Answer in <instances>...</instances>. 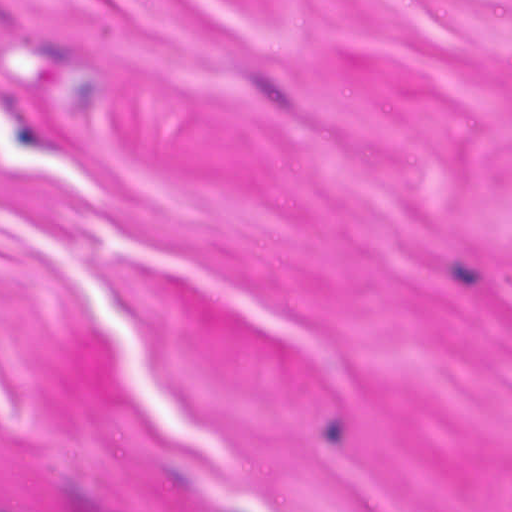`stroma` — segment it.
Instances as JSON below:
<instances>
[{
  "mask_svg": "<svg viewBox=\"0 0 512 512\" xmlns=\"http://www.w3.org/2000/svg\"><path fill=\"white\" fill-rule=\"evenodd\" d=\"M0 512H512V0H0Z\"/></svg>",
  "mask_w": 512,
  "mask_h": 512,
  "instance_id": "obj_1",
  "label": "stroma"
}]
</instances>
